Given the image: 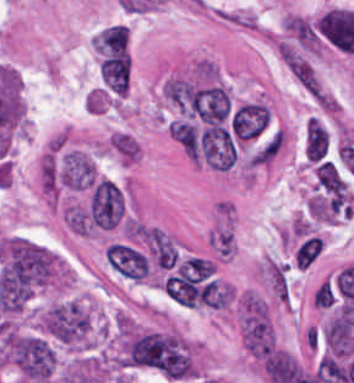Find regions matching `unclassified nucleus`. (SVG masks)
Instances as JSON below:
<instances>
[{
    "label": "unclassified nucleus",
    "instance_id": "unclassified-nucleus-3",
    "mask_svg": "<svg viewBox=\"0 0 354 383\" xmlns=\"http://www.w3.org/2000/svg\"><path fill=\"white\" fill-rule=\"evenodd\" d=\"M149 249L159 267L169 268L178 254L173 243L162 230L150 228Z\"/></svg>",
    "mask_w": 354,
    "mask_h": 383
},
{
    "label": "unclassified nucleus",
    "instance_id": "unclassified-nucleus-1",
    "mask_svg": "<svg viewBox=\"0 0 354 383\" xmlns=\"http://www.w3.org/2000/svg\"><path fill=\"white\" fill-rule=\"evenodd\" d=\"M123 211V195L117 184L101 178L92 188L89 199V215L102 228H111Z\"/></svg>",
    "mask_w": 354,
    "mask_h": 383
},
{
    "label": "unclassified nucleus",
    "instance_id": "unclassified-nucleus-2",
    "mask_svg": "<svg viewBox=\"0 0 354 383\" xmlns=\"http://www.w3.org/2000/svg\"><path fill=\"white\" fill-rule=\"evenodd\" d=\"M97 178L94 163L86 153L72 150L63 157L58 170L60 185L74 189H90Z\"/></svg>",
    "mask_w": 354,
    "mask_h": 383
}]
</instances>
